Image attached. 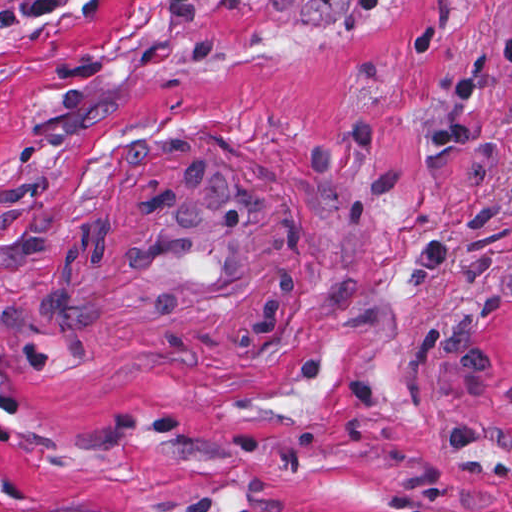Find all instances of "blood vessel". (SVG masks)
Wrapping results in <instances>:
<instances>
[{
  "label": "blood vessel",
  "mask_w": 512,
  "mask_h": 512,
  "mask_svg": "<svg viewBox=\"0 0 512 512\" xmlns=\"http://www.w3.org/2000/svg\"><path fill=\"white\" fill-rule=\"evenodd\" d=\"M100 286L143 304H238L272 285L266 209L217 157L165 175L99 228Z\"/></svg>",
  "instance_id": "1"
}]
</instances>
